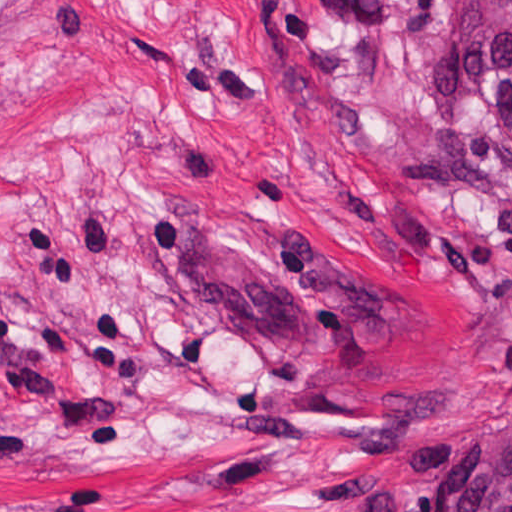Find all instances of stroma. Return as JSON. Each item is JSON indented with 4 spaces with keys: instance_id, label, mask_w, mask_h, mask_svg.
Wrapping results in <instances>:
<instances>
[{
    "instance_id": "stroma-1",
    "label": "stroma",
    "mask_w": 512,
    "mask_h": 512,
    "mask_svg": "<svg viewBox=\"0 0 512 512\" xmlns=\"http://www.w3.org/2000/svg\"><path fill=\"white\" fill-rule=\"evenodd\" d=\"M451 1L0 0V512L440 511L512 427Z\"/></svg>"
}]
</instances>
